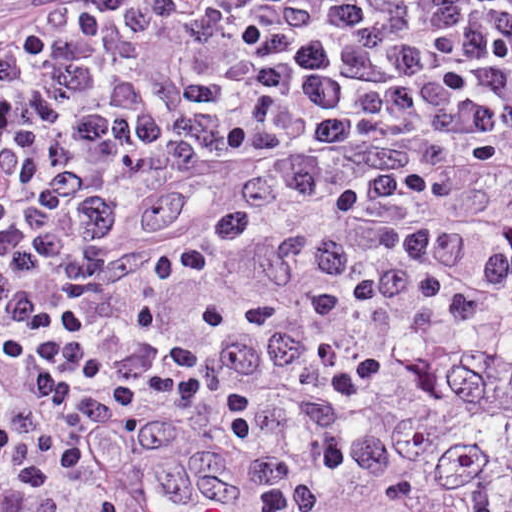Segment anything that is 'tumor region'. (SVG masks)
<instances>
[{
    "label": "tumor region",
    "instance_id": "tumor-region-1",
    "mask_svg": "<svg viewBox=\"0 0 512 512\" xmlns=\"http://www.w3.org/2000/svg\"><path fill=\"white\" fill-rule=\"evenodd\" d=\"M275 512H512V324L380 398Z\"/></svg>",
    "mask_w": 512,
    "mask_h": 512
}]
</instances>
